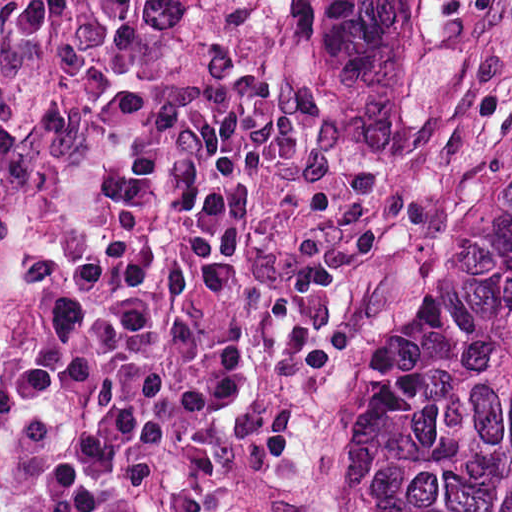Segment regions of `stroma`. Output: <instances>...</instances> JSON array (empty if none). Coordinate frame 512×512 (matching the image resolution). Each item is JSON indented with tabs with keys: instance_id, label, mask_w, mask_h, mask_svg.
<instances>
[{
	"instance_id": "35a3bbf8",
	"label": "stroma",
	"mask_w": 512,
	"mask_h": 512,
	"mask_svg": "<svg viewBox=\"0 0 512 512\" xmlns=\"http://www.w3.org/2000/svg\"><path fill=\"white\" fill-rule=\"evenodd\" d=\"M191 83L250 85L411 203L417 279L367 333L335 473L306 501V512H358L356 459L410 400L512 186V13L485 86L450 112L376 131L318 86L289 43L285 0H0V285L56 175L146 99Z\"/></svg>"
}]
</instances>
